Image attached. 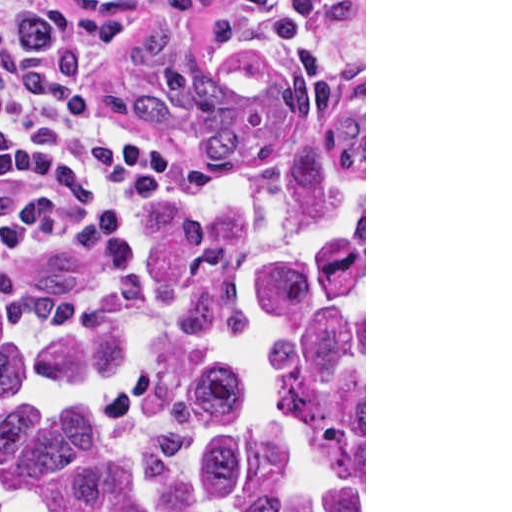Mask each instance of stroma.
<instances>
[{"mask_svg": "<svg viewBox=\"0 0 512 512\" xmlns=\"http://www.w3.org/2000/svg\"><path fill=\"white\" fill-rule=\"evenodd\" d=\"M83 4L80 0H71ZM86 6V5H85ZM247 47L290 87L313 96L364 104V512H366V0H272L262 9L225 5ZM123 42L111 51V84L121 97ZM177 145V144H176ZM178 146V145H177ZM186 185L139 203L106 210H67L0 229V265L39 252L81 224L125 214L178 210L191 204L202 174L180 146Z\"/></svg>", "mask_w": 512, "mask_h": 512, "instance_id": "1", "label": "stroma"}]
</instances>
